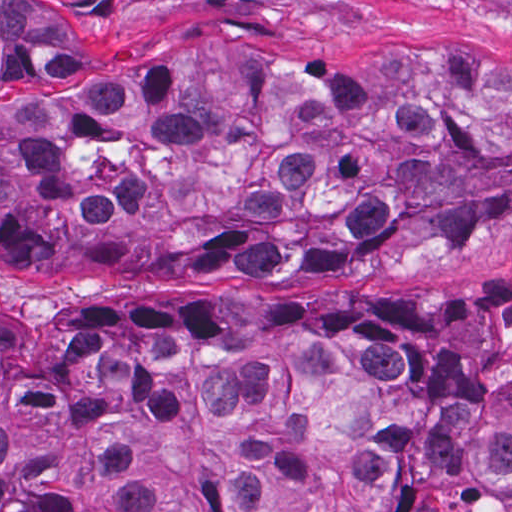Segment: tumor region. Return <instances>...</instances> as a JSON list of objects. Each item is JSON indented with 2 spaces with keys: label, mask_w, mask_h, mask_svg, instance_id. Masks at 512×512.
Here are the masks:
<instances>
[{
  "label": "tumor region",
  "mask_w": 512,
  "mask_h": 512,
  "mask_svg": "<svg viewBox=\"0 0 512 512\" xmlns=\"http://www.w3.org/2000/svg\"><path fill=\"white\" fill-rule=\"evenodd\" d=\"M293 1H0V262L142 282L512 228V56L188 45ZM0 512H512V277L0 306Z\"/></svg>",
  "instance_id": "1"
}]
</instances>
